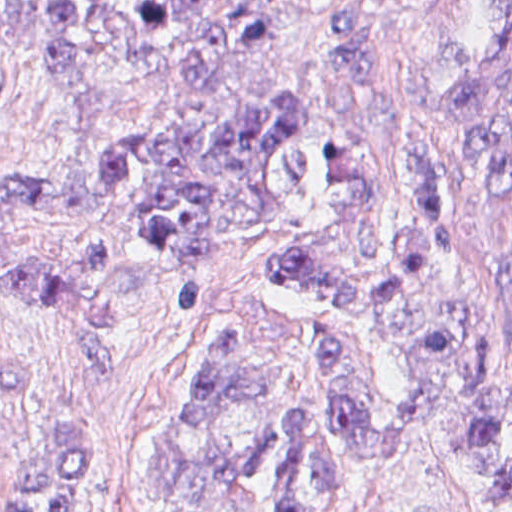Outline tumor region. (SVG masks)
<instances>
[{"mask_svg":"<svg viewBox=\"0 0 512 512\" xmlns=\"http://www.w3.org/2000/svg\"><path fill=\"white\" fill-rule=\"evenodd\" d=\"M324 17L327 61L404 190L396 273L373 157L331 137L313 174V109L283 92L209 126L120 135L96 190L0 177V282L68 322L107 375L117 314L141 282L179 314L202 312L214 250L278 226L277 184H302L324 210L261 275L331 310L296 324L249 298L226 310L191 365L144 512H355L418 447L465 461L493 512H512V71L495 54L438 49L393 89L372 14L336 3ZM275 38L261 1L126 13L0 1V39L35 48L46 83L92 106L119 104L79 61L104 44L200 83ZM99 492L97 434L69 429L37 443L0 512H92Z\"/></svg>","mask_w":512,"mask_h":512,"instance_id":"obj_1","label":"tumor region"}]
</instances>
